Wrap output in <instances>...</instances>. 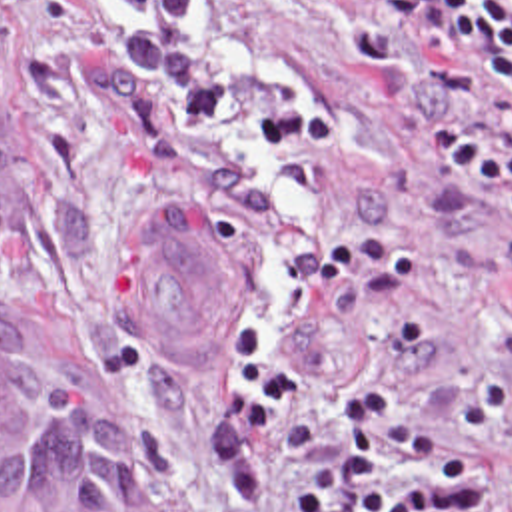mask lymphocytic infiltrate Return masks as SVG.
Segmentation results:
<instances>
[{
    "label": "lymphocytic infiltrate",
    "instance_id": "obj_1",
    "mask_svg": "<svg viewBox=\"0 0 512 512\" xmlns=\"http://www.w3.org/2000/svg\"><path fill=\"white\" fill-rule=\"evenodd\" d=\"M348 10L394 24L428 22L456 66L500 80L512 102V0H338Z\"/></svg>",
    "mask_w": 512,
    "mask_h": 512
}]
</instances>
